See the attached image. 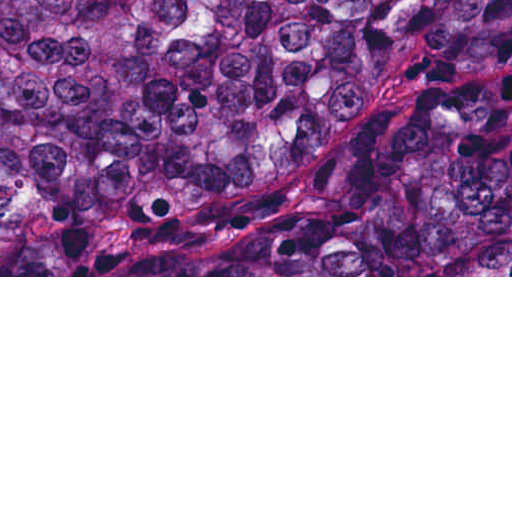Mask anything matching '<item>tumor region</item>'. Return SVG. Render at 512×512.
<instances>
[{
    "mask_svg": "<svg viewBox=\"0 0 512 512\" xmlns=\"http://www.w3.org/2000/svg\"><path fill=\"white\" fill-rule=\"evenodd\" d=\"M0 275H512V0H0Z\"/></svg>",
    "mask_w": 512,
    "mask_h": 512,
    "instance_id": "tumor-region-1",
    "label": "tumor region"
}]
</instances>
